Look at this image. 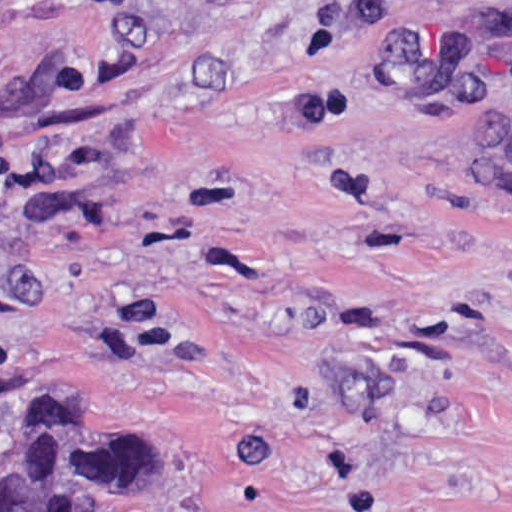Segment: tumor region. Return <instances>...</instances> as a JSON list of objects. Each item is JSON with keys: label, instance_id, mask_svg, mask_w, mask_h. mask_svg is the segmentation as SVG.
Here are the masks:
<instances>
[{"label": "tumor region", "instance_id": "e687c5a6", "mask_svg": "<svg viewBox=\"0 0 512 512\" xmlns=\"http://www.w3.org/2000/svg\"><path fill=\"white\" fill-rule=\"evenodd\" d=\"M267 0H195L201 28ZM156 439L119 415H79L0 469V512H150Z\"/></svg>", "mask_w": 512, "mask_h": 512}]
</instances>
